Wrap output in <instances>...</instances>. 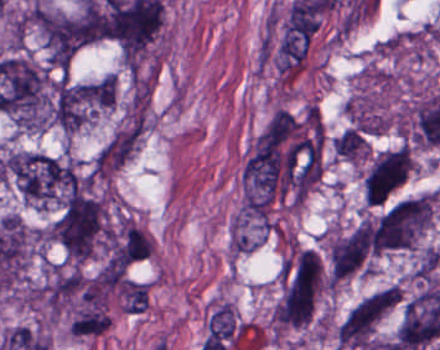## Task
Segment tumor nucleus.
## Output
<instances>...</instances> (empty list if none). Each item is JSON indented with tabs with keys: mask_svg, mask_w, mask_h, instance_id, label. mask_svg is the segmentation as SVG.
<instances>
[{
	"mask_svg": "<svg viewBox=\"0 0 440 350\" xmlns=\"http://www.w3.org/2000/svg\"><path fill=\"white\" fill-rule=\"evenodd\" d=\"M410 171L409 150H383L376 154L362 177L365 201L382 203Z\"/></svg>",
	"mask_w": 440,
	"mask_h": 350,
	"instance_id": "tumor-nucleus-5",
	"label": "tumor nucleus"
},
{
	"mask_svg": "<svg viewBox=\"0 0 440 350\" xmlns=\"http://www.w3.org/2000/svg\"><path fill=\"white\" fill-rule=\"evenodd\" d=\"M139 127H125L116 131L99 149L93 159V172L109 176L131 156L140 141Z\"/></svg>",
	"mask_w": 440,
	"mask_h": 350,
	"instance_id": "tumor-nucleus-6",
	"label": "tumor nucleus"
},
{
	"mask_svg": "<svg viewBox=\"0 0 440 350\" xmlns=\"http://www.w3.org/2000/svg\"><path fill=\"white\" fill-rule=\"evenodd\" d=\"M108 325L109 319L104 305H79L73 313L68 332L78 337H95Z\"/></svg>",
	"mask_w": 440,
	"mask_h": 350,
	"instance_id": "tumor-nucleus-7",
	"label": "tumor nucleus"
},
{
	"mask_svg": "<svg viewBox=\"0 0 440 350\" xmlns=\"http://www.w3.org/2000/svg\"><path fill=\"white\" fill-rule=\"evenodd\" d=\"M433 197L418 195L394 202L376 220L374 252L384 254L413 249L432 215Z\"/></svg>",
	"mask_w": 440,
	"mask_h": 350,
	"instance_id": "tumor-nucleus-3",
	"label": "tumor nucleus"
},
{
	"mask_svg": "<svg viewBox=\"0 0 440 350\" xmlns=\"http://www.w3.org/2000/svg\"><path fill=\"white\" fill-rule=\"evenodd\" d=\"M0 170L20 196L36 207L93 196L88 177L62 156L12 152L1 160Z\"/></svg>",
	"mask_w": 440,
	"mask_h": 350,
	"instance_id": "tumor-nucleus-1",
	"label": "tumor nucleus"
},
{
	"mask_svg": "<svg viewBox=\"0 0 440 350\" xmlns=\"http://www.w3.org/2000/svg\"><path fill=\"white\" fill-rule=\"evenodd\" d=\"M123 250L126 258L144 259L151 252V242L145 235L132 226H125Z\"/></svg>",
	"mask_w": 440,
	"mask_h": 350,
	"instance_id": "tumor-nucleus-8",
	"label": "tumor nucleus"
},
{
	"mask_svg": "<svg viewBox=\"0 0 440 350\" xmlns=\"http://www.w3.org/2000/svg\"><path fill=\"white\" fill-rule=\"evenodd\" d=\"M108 235L104 202L78 191L62 200L48 228L53 243L66 259L74 262L94 254Z\"/></svg>",
	"mask_w": 440,
	"mask_h": 350,
	"instance_id": "tumor-nucleus-2",
	"label": "tumor nucleus"
},
{
	"mask_svg": "<svg viewBox=\"0 0 440 350\" xmlns=\"http://www.w3.org/2000/svg\"><path fill=\"white\" fill-rule=\"evenodd\" d=\"M373 233L372 222L361 220L332 238L326 248L327 278L341 280L367 272Z\"/></svg>",
	"mask_w": 440,
	"mask_h": 350,
	"instance_id": "tumor-nucleus-4",
	"label": "tumor nucleus"
}]
</instances>
